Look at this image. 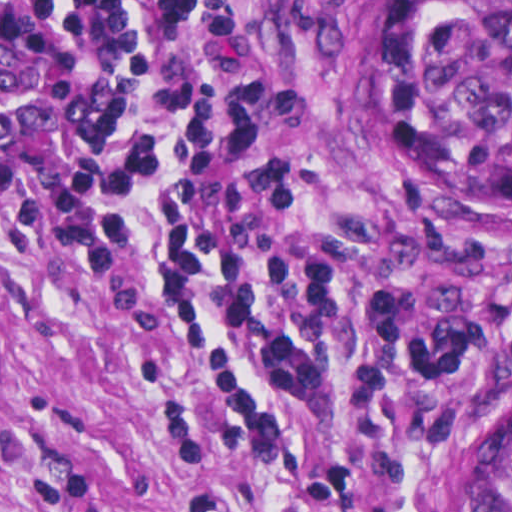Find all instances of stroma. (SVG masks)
Returning <instances> with one entry per match:
<instances>
[{
    "label": "stroma",
    "instance_id": "obj_1",
    "mask_svg": "<svg viewBox=\"0 0 512 512\" xmlns=\"http://www.w3.org/2000/svg\"><path fill=\"white\" fill-rule=\"evenodd\" d=\"M258 1L298 44L306 164L354 239L403 266L512 262V232L456 228L409 169L396 68L404 0ZM503 384L420 434L387 509L218 489L181 460L67 255L0 193V512H478L481 431Z\"/></svg>",
    "mask_w": 512,
    "mask_h": 512
}]
</instances>
